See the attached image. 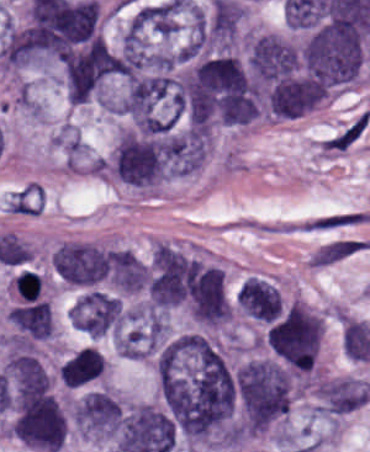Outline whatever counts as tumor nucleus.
I'll list each match as a JSON object with an SVG mask.
<instances>
[{
  "instance_id": "tumor-nucleus-1",
  "label": "tumor nucleus",
  "mask_w": 370,
  "mask_h": 452,
  "mask_svg": "<svg viewBox=\"0 0 370 452\" xmlns=\"http://www.w3.org/2000/svg\"><path fill=\"white\" fill-rule=\"evenodd\" d=\"M154 402L176 452L233 450L229 363L211 335L170 330L152 368Z\"/></svg>"
},
{
  "instance_id": "tumor-nucleus-2",
  "label": "tumor nucleus",
  "mask_w": 370,
  "mask_h": 452,
  "mask_svg": "<svg viewBox=\"0 0 370 452\" xmlns=\"http://www.w3.org/2000/svg\"><path fill=\"white\" fill-rule=\"evenodd\" d=\"M231 381L239 420L248 431H262L285 416L290 375L270 358H250L233 369Z\"/></svg>"
},
{
  "instance_id": "tumor-nucleus-3",
  "label": "tumor nucleus",
  "mask_w": 370,
  "mask_h": 452,
  "mask_svg": "<svg viewBox=\"0 0 370 452\" xmlns=\"http://www.w3.org/2000/svg\"><path fill=\"white\" fill-rule=\"evenodd\" d=\"M322 326L320 316L301 301H292L269 325V346L295 368H309Z\"/></svg>"
},
{
  "instance_id": "tumor-nucleus-4",
  "label": "tumor nucleus",
  "mask_w": 370,
  "mask_h": 452,
  "mask_svg": "<svg viewBox=\"0 0 370 452\" xmlns=\"http://www.w3.org/2000/svg\"><path fill=\"white\" fill-rule=\"evenodd\" d=\"M54 267L65 284L92 287L107 279L106 247L87 242L64 243L55 247Z\"/></svg>"
},
{
  "instance_id": "tumor-nucleus-5",
  "label": "tumor nucleus",
  "mask_w": 370,
  "mask_h": 452,
  "mask_svg": "<svg viewBox=\"0 0 370 452\" xmlns=\"http://www.w3.org/2000/svg\"><path fill=\"white\" fill-rule=\"evenodd\" d=\"M369 400L367 381L343 377L332 378L317 385L314 410L324 417L338 418Z\"/></svg>"
},
{
  "instance_id": "tumor-nucleus-6",
  "label": "tumor nucleus",
  "mask_w": 370,
  "mask_h": 452,
  "mask_svg": "<svg viewBox=\"0 0 370 452\" xmlns=\"http://www.w3.org/2000/svg\"><path fill=\"white\" fill-rule=\"evenodd\" d=\"M104 359L96 348L84 347L60 364L58 376L66 387H79L101 378Z\"/></svg>"
},
{
  "instance_id": "tumor-nucleus-7",
  "label": "tumor nucleus",
  "mask_w": 370,
  "mask_h": 452,
  "mask_svg": "<svg viewBox=\"0 0 370 452\" xmlns=\"http://www.w3.org/2000/svg\"><path fill=\"white\" fill-rule=\"evenodd\" d=\"M6 319L32 339H46L49 336V305L43 300L15 307L6 314Z\"/></svg>"
},
{
  "instance_id": "tumor-nucleus-8",
  "label": "tumor nucleus",
  "mask_w": 370,
  "mask_h": 452,
  "mask_svg": "<svg viewBox=\"0 0 370 452\" xmlns=\"http://www.w3.org/2000/svg\"><path fill=\"white\" fill-rule=\"evenodd\" d=\"M13 287L18 299L22 301H34L39 296V277L29 270H22L13 279Z\"/></svg>"
}]
</instances>
